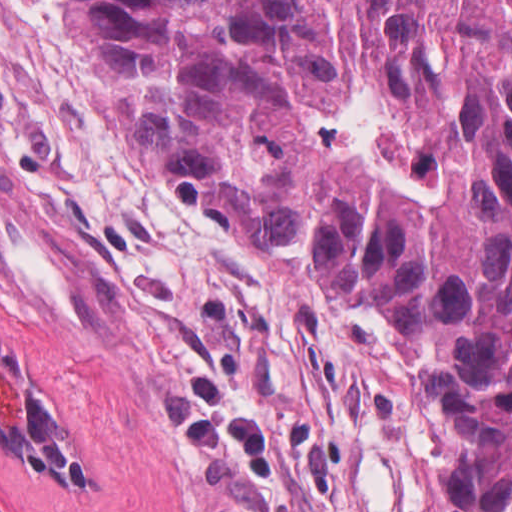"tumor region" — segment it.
<instances>
[{
	"instance_id": "obj_1",
	"label": "tumor region",
	"mask_w": 512,
	"mask_h": 512,
	"mask_svg": "<svg viewBox=\"0 0 512 512\" xmlns=\"http://www.w3.org/2000/svg\"><path fill=\"white\" fill-rule=\"evenodd\" d=\"M72 12L191 203L383 307L405 335L450 425L455 512H512V0ZM0 435L91 479L81 440L2 342Z\"/></svg>"
}]
</instances>
